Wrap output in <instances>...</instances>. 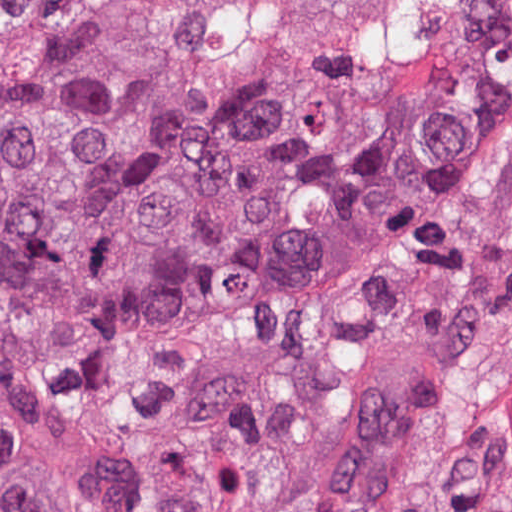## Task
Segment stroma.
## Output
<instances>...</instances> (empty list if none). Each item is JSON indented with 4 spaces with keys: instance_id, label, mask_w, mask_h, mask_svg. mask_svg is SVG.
<instances>
[{
    "instance_id": "stroma-1",
    "label": "stroma",
    "mask_w": 512,
    "mask_h": 512,
    "mask_svg": "<svg viewBox=\"0 0 512 512\" xmlns=\"http://www.w3.org/2000/svg\"><path fill=\"white\" fill-rule=\"evenodd\" d=\"M325 512H512V231Z\"/></svg>"
}]
</instances>
